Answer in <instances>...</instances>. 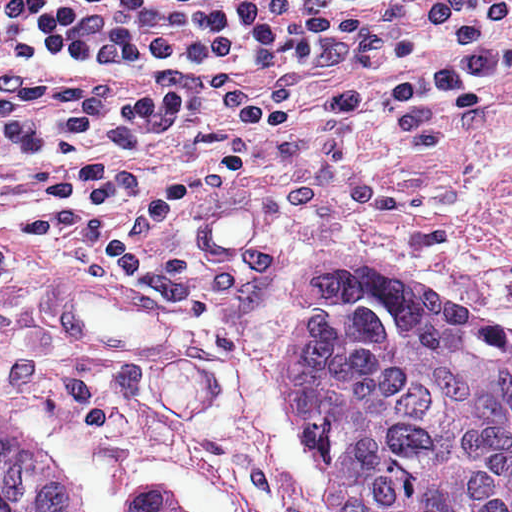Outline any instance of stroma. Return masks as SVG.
Instances as JSON below:
<instances>
[{
	"mask_svg": "<svg viewBox=\"0 0 512 512\" xmlns=\"http://www.w3.org/2000/svg\"><path fill=\"white\" fill-rule=\"evenodd\" d=\"M192 85L254 95L144 134L155 178L192 174L228 136L279 153L255 180L174 202L152 233L154 271L197 301L115 284L90 239L21 248L0 264V397L50 432L91 512L146 493L194 512H332L278 363L302 256L394 251L512 328V65L350 128V108L255 66L37 70L0 79V102Z\"/></svg>",
	"mask_w": 512,
	"mask_h": 512,
	"instance_id": "obj_1",
	"label": "stroma"
}]
</instances>
